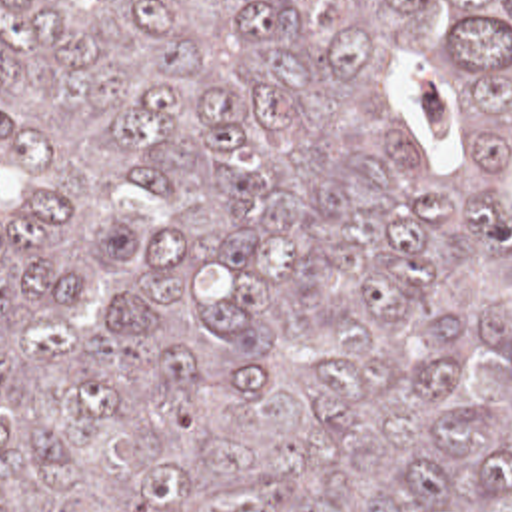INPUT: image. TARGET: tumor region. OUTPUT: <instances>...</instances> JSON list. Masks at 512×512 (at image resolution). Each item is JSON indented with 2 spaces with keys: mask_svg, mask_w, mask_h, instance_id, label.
Here are the masks:
<instances>
[{
  "mask_svg": "<svg viewBox=\"0 0 512 512\" xmlns=\"http://www.w3.org/2000/svg\"><path fill=\"white\" fill-rule=\"evenodd\" d=\"M0 512H512V0H0Z\"/></svg>",
  "mask_w": 512,
  "mask_h": 512,
  "instance_id": "tumor-region-1",
  "label": "tumor region"
}]
</instances>
